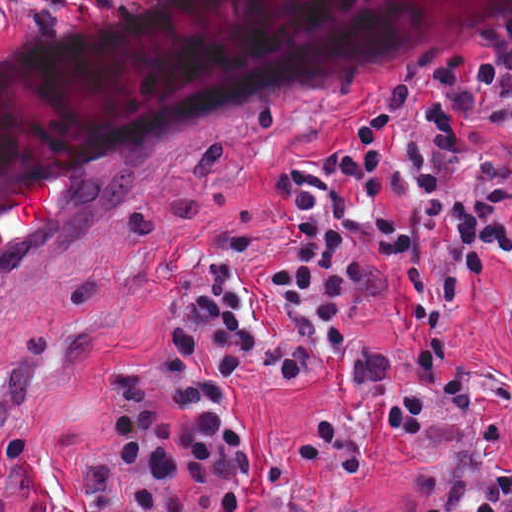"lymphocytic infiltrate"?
<instances>
[{"label": "lymphocytic infiltrate", "instance_id": "1", "mask_svg": "<svg viewBox=\"0 0 512 512\" xmlns=\"http://www.w3.org/2000/svg\"><path fill=\"white\" fill-rule=\"evenodd\" d=\"M459 512H512V488Z\"/></svg>", "mask_w": 512, "mask_h": 512}]
</instances>
